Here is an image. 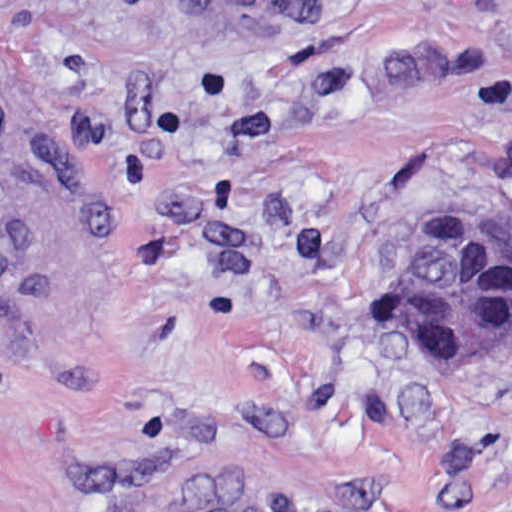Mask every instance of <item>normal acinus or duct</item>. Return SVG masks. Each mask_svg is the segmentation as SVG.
I'll return each instance as SVG.
<instances>
[{
    "label": "normal acinus or duct",
    "instance_id": "1",
    "mask_svg": "<svg viewBox=\"0 0 512 512\" xmlns=\"http://www.w3.org/2000/svg\"><path fill=\"white\" fill-rule=\"evenodd\" d=\"M390 333L408 359L511 344L512 237L465 222L436 238L414 277L391 294Z\"/></svg>",
    "mask_w": 512,
    "mask_h": 512
}]
</instances>
